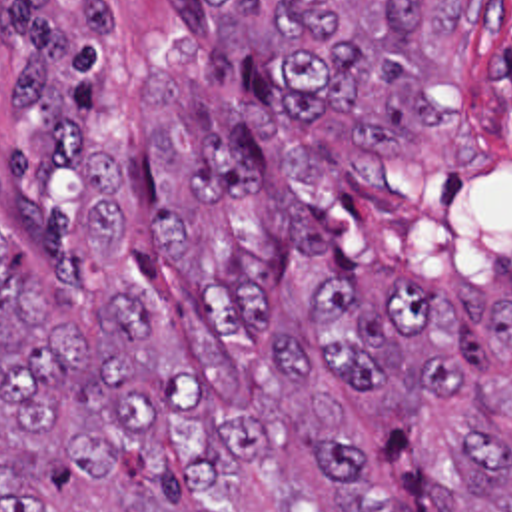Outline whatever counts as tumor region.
<instances>
[{"mask_svg": "<svg viewBox=\"0 0 512 512\" xmlns=\"http://www.w3.org/2000/svg\"><path fill=\"white\" fill-rule=\"evenodd\" d=\"M198 23L92 51L22 0L2 85L0 404L114 480L142 452L170 512H404L314 384L467 398L438 512H512V308L356 267V145L434 127L439 51L493 0H194ZM24 273H22V267ZM230 396H242L232 400ZM0 512H48L38 494Z\"/></svg>", "mask_w": 512, "mask_h": 512, "instance_id": "e687c5a6", "label": "tumor region"}]
</instances>
